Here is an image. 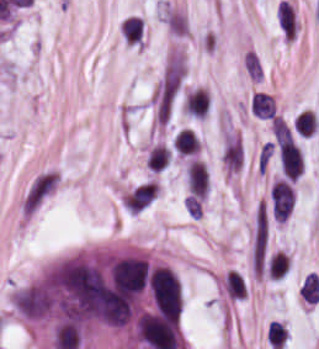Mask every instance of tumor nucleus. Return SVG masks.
Here are the masks:
<instances>
[{"mask_svg":"<svg viewBox=\"0 0 319 349\" xmlns=\"http://www.w3.org/2000/svg\"><path fill=\"white\" fill-rule=\"evenodd\" d=\"M151 298L155 310L178 320L182 297L178 281L167 266H153L149 274Z\"/></svg>","mask_w":319,"mask_h":349,"instance_id":"2f306a5c","label":"tumor nucleus"},{"mask_svg":"<svg viewBox=\"0 0 319 349\" xmlns=\"http://www.w3.org/2000/svg\"><path fill=\"white\" fill-rule=\"evenodd\" d=\"M12 302L18 315L31 321L46 318L51 312V302L37 278L14 290Z\"/></svg>","mask_w":319,"mask_h":349,"instance_id":"8643909e","label":"tumor nucleus"},{"mask_svg":"<svg viewBox=\"0 0 319 349\" xmlns=\"http://www.w3.org/2000/svg\"><path fill=\"white\" fill-rule=\"evenodd\" d=\"M276 18L284 37L293 40L298 26L293 5L282 0L276 10Z\"/></svg>","mask_w":319,"mask_h":349,"instance_id":"5ab6c2c4","label":"tumor nucleus"},{"mask_svg":"<svg viewBox=\"0 0 319 349\" xmlns=\"http://www.w3.org/2000/svg\"><path fill=\"white\" fill-rule=\"evenodd\" d=\"M120 37L126 44L138 45L143 40L141 16L128 15L120 21Z\"/></svg>","mask_w":319,"mask_h":349,"instance_id":"2cbd58db","label":"tumor nucleus"}]
</instances>
